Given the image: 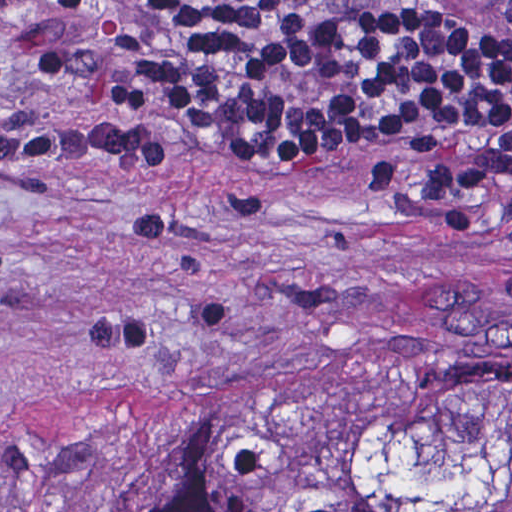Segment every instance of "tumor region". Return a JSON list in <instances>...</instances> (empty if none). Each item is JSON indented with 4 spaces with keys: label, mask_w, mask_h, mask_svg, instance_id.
Returning a JSON list of instances; mask_svg holds the SVG:
<instances>
[{
    "label": "tumor region",
    "mask_w": 512,
    "mask_h": 512,
    "mask_svg": "<svg viewBox=\"0 0 512 512\" xmlns=\"http://www.w3.org/2000/svg\"><path fill=\"white\" fill-rule=\"evenodd\" d=\"M86 512H512V363L439 358L123 449Z\"/></svg>",
    "instance_id": "obj_1"
}]
</instances>
